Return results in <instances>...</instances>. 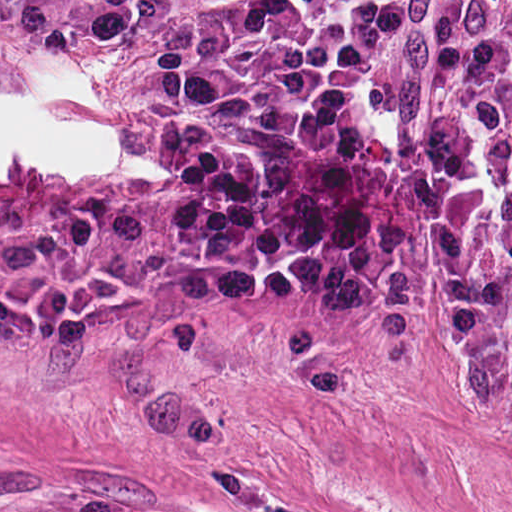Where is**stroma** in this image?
Masks as SVG:
<instances>
[{"instance_id": "35a3bbf8", "label": "stroma", "mask_w": 512, "mask_h": 512, "mask_svg": "<svg viewBox=\"0 0 512 512\" xmlns=\"http://www.w3.org/2000/svg\"><path fill=\"white\" fill-rule=\"evenodd\" d=\"M101 48L0 33V512H512V423L440 378L405 150L456 93L411 0L387 80L313 160L301 244L234 298L186 289L154 161L175 12Z\"/></svg>"}]
</instances>
